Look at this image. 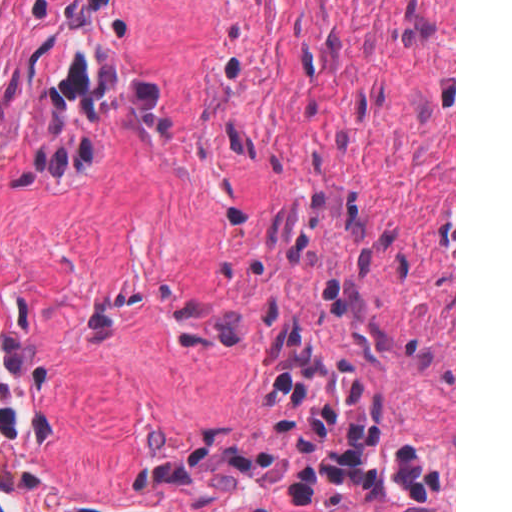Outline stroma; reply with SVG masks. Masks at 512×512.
Masks as SVG:
<instances>
[{
  "label": "stroma",
  "instance_id": "35a3bbf8",
  "mask_svg": "<svg viewBox=\"0 0 512 512\" xmlns=\"http://www.w3.org/2000/svg\"><path fill=\"white\" fill-rule=\"evenodd\" d=\"M454 406L224 0H0V512H272Z\"/></svg>",
  "mask_w": 512,
  "mask_h": 512
}]
</instances>
